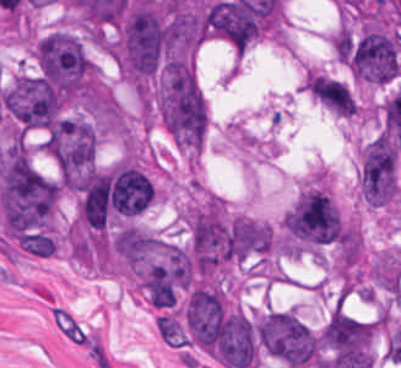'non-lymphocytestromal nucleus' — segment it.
<instances>
[{
  "label": "non-lymphocyte stromal nucleus",
  "mask_w": 401,
  "mask_h": 368,
  "mask_svg": "<svg viewBox=\"0 0 401 368\" xmlns=\"http://www.w3.org/2000/svg\"><path fill=\"white\" fill-rule=\"evenodd\" d=\"M53 319L63 336L91 351H102V336L73 310L54 306Z\"/></svg>",
  "instance_id": "obj_1"
}]
</instances>
